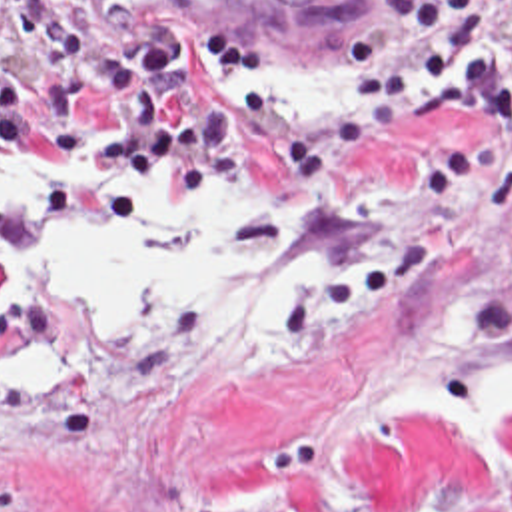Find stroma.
Wrapping results in <instances>:
<instances>
[{"label":"stroma","mask_w":512,"mask_h":512,"mask_svg":"<svg viewBox=\"0 0 512 512\" xmlns=\"http://www.w3.org/2000/svg\"><path fill=\"white\" fill-rule=\"evenodd\" d=\"M0 0V145L54 153L52 209L0 213V512H512V431L460 441L416 405L512 357V143L474 107L290 127L210 97L224 69L56 39ZM264 177L344 257L292 343L146 309L94 343L3 259L72 213L120 233L102 181Z\"/></svg>","instance_id":"obj_1"}]
</instances>
